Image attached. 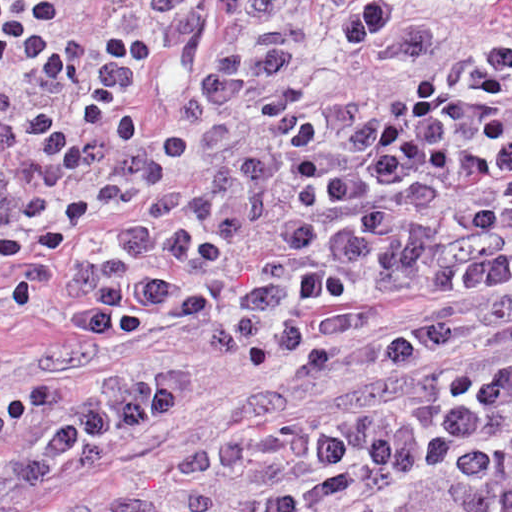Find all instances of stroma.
Returning <instances> with one entry per match:
<instances>
[{"label": "stroma", "mask_w": 512, "mask_h": 512, "mask_svg": "<svg viewBox=\"0 0 512 512\" xmlns=\"http://www.w3.org/2000/svg\"><path fill=\"white\" fill-rule=\"evenodd\" d=\"M355 0H59L56 39L145 32L157 55L139 103L166 138L238 117L293 78L347 49L335 14ZM401 31L486 14L512 0H395ZM141 362L182 369V411L154 438L120 448L1 512H64L228 440L263 394V380L229 357L200 351L182 326L131 337H88L40 320L0 327V401L60 378Z\"/></svg>", "instance_id": "stroma-1"}]
</instances>
